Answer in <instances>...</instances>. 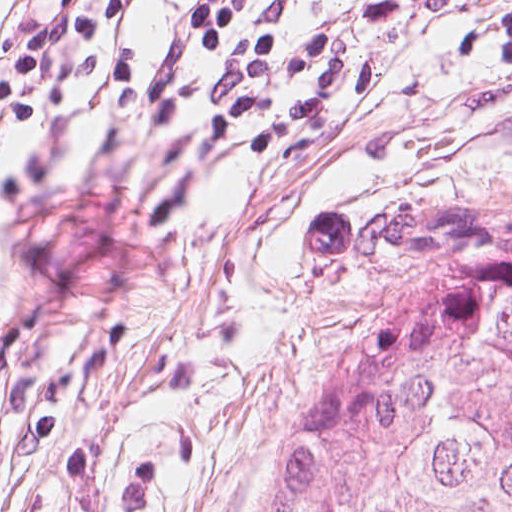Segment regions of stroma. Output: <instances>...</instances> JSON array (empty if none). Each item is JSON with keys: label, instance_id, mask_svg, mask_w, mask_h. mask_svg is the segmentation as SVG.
<instances>
[{"label": "stroma", "instance_id": "obj_1", "mask_svg": "<svg viewBox=\"0 0 512 512\" xmlns=\"http://www.w3.org/2000/svg\"><path fill=\"white\" fill-rule=\"evenodd\" d=\"M198 0H166L109 118L41 122L0 144V219L64 197L67 285L83 330H131L49 440L0 405V512H271L337 266L306 226L410 186L512 206V69L458 62L512 0H407L394 23L304 0L386 61L401 94L374 123L225 200L191 247L152 223ZM33 0H0V58ZM295 240H297L295 242ZM295 242V243H294ZM16 268L0 225V307Z\"/></svg>", "mask_w": 512, "mask_h": 512}]
</instances>
